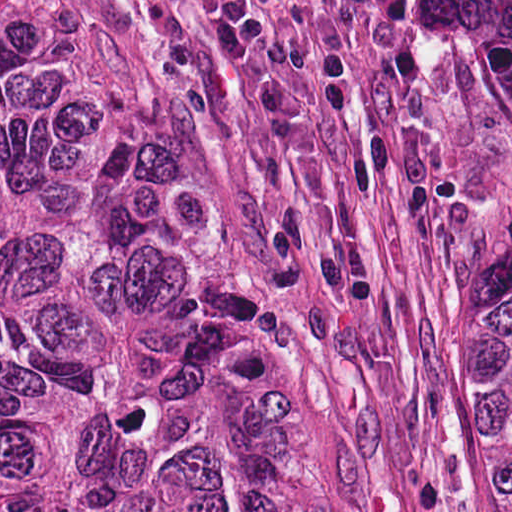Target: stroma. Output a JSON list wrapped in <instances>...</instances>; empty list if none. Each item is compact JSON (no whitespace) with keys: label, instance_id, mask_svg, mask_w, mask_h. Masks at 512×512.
<instances>
[{"label":"stroma","instance_id":"obj_1","mask_svg":"<svg viewBox=\"0 0 512 512\" xmlns=\"http://www.w3.org/2000/svg\"><path fill=\"white\" fill-rule=\"evenodd\" d=\"M107 24L136 83L248 120L263 288L301 443L342 512H510L457 369L397 123L404 0H259L254 55L199 0H31Z\"/></svg>","mask_w":512,"mask_h":512}]
</instances>
